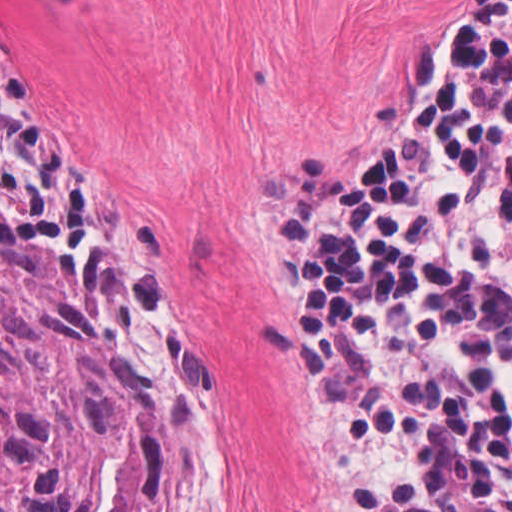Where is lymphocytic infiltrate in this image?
Instances as JSON below:
<instances>
[{"instance_id": "lymphocytic-infiltrate-1", "label": "lymphocytic infiltrate", "mask_w": 512, "mask_h": 512, "mask_svg": "<svg viewBox=\"0 0 512 512\" xmlns=\"http://www.w3.org/2000/svg\"><path fill=\"white\" fill-rule=\"evenodd\" d=\"M0 186L73 176L0 54ZM311 434L343 512H512V0L449 9L388 143L279 207Z\"/></svg>"}]
</instances>
